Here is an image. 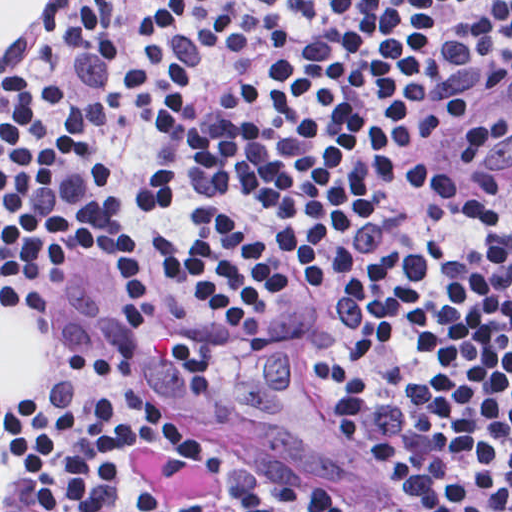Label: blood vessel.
<instances>
[{"mask_svg":"<svg viewBox=\"0 0 512 512\" xmlns=\"http://www.w3.org/2000/svg\"><path fill=\"white\" fill-rule=\"evenodd\" d=\"M463 171L480 184H512V82L469 139Z\"/></svg>","mask_w":512,"mask_h":512,"instance_id":"blood-vessel-1","label":"blood vessel"}]
</instances>
